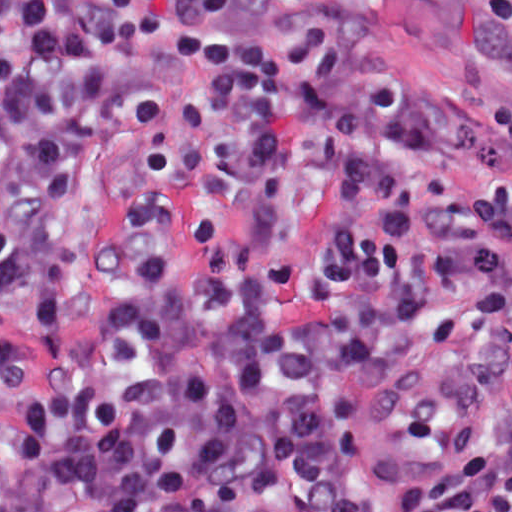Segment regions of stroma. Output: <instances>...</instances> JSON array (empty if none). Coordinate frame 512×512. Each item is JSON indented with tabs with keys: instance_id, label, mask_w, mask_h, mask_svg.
<instances>
[{
	"instance_id": "1",
	"label": "stroma",
	"mask_w": 512,
	"mask_h": 512,
	"mask_svg": "<svg viewBox=\"0 0 512 512\" xmlns=\"http://www.w3.org/2000/svg\"><path fill=\"white\" fill-rule=\"evenodd\" d=\"M303 3H337L372 22L385 70L410 90L441 100L436 125L443 136L437 158L439 186L420 199L413 217L416 239L433 251L496 248L512 263V236L483 219L478 193L491 167L474 144L490 130V117L512 105V28L483 18L471 50L462 46L447 18L420 0H242L166 28L142 58V84L154 101L147 117L118 130L98 154L73 195L72 292L54 325L60 350L91 341L101 323L105 285L101 256L90 242L139 173L143 145L182 101L189 36L235 35L268 22L275 12ZM0 512H1V0H0Z\"/></svg>"
}]
</instances>
